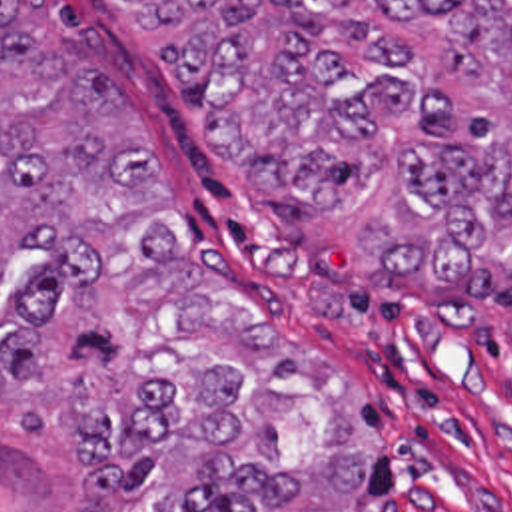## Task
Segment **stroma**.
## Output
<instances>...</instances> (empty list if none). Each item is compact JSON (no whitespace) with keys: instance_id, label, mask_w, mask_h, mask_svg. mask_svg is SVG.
<instances>
[{"instance_id":"35a3bbf8","label":"stroma","mask_w":512,"mask_h":512,"mask_svg":"<svg viewBox=\"0 0 512 512\" xmlns=\"http://www.w3.org/2000/svg\"><path fill=\"white\" fill-rule=\"evenodd\" d=\"M48 15L82 79L124 97L162 161L170 251L334 364L370 450L348 512H512V249L476 281L370 277L350 235L224 175L118 0H48ZM46 261L42 249L8 259L0 323ZM0 512H94L46 462L12 388Z\"/></svg>"}]
</instances>
